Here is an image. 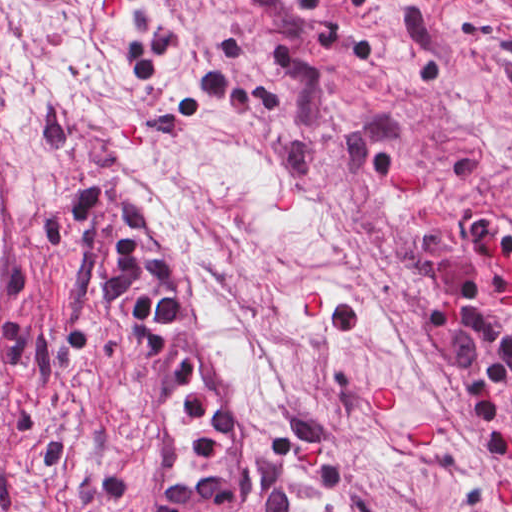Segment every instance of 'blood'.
<instances>
[{
	"label": "blood",
	"mask_w": 512,
	"mask_h": 512,
	"mask_svg": "<svg viewBox=\"0 0 512 512\" xmlns=\"http://www.w3.org/2000/svg\"><path fill=\"white\" fill-rule=\"evenodd\" d=\"M105 5L109 15L125 13V0H105ZM491 262L496 269L507 274L512 280V261L507 254H496ZM504 303L506 309L512 311V287L504 291ZM303 304L306 316H316L319 312V294L314 289L305 293ZM394 403L395 386L390 381L371 387L368 408L373 413H385ZM410 442L412 447H427L430 444L429 427L423 424L411 430Z\"/></svg>",
	"instance_id": "1a1defca"
}]
</instances>
